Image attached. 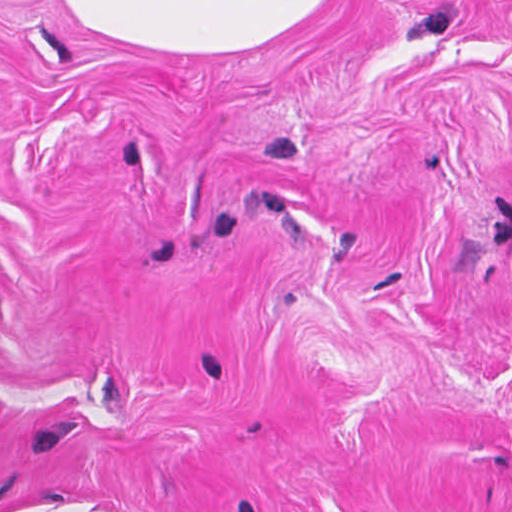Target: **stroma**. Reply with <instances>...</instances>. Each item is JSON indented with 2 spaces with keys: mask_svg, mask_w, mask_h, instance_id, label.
<instances>
[{
  "mask_svg": "<svg viewBox=\"0 0 512 512\" xmlns=\"http://www.w3.org/2000/svg\"><path fill=\"white\" fill-rule=\"evenodd\" d=\"M0 512H512V0H0Z\"/></svg>",
  "mask_w": 512,
  "mask_h": 512,
  "instance_id": "1",
  "label": "stroma"
}]
</instances>
